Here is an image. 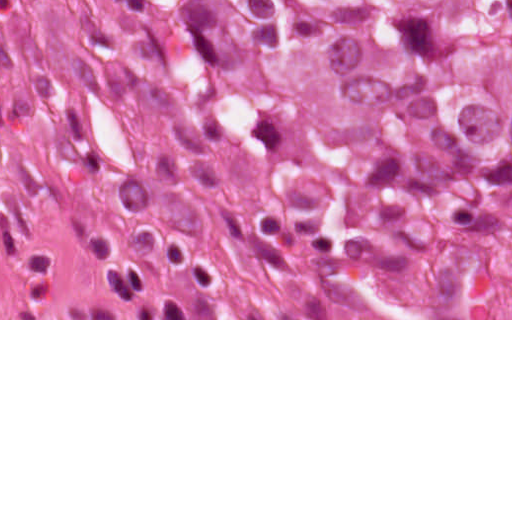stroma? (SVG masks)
Listing matches in <instances>:
<instances>
[{"label": "stroma", "instance_id": "35a3bbf8", "mask_svg": "<svg viewBox=\"0 0 512 512\" xmlns=\"http://www.w3.org/2000/svg\"><path fill=\"white\" fill-rule=\"evenodd\" d=\"M143 133L125 87L0 0V320L199 319L155 282Z\"/></svg>", "mask_w": 512, "mask_h": 512}]
</instances>
